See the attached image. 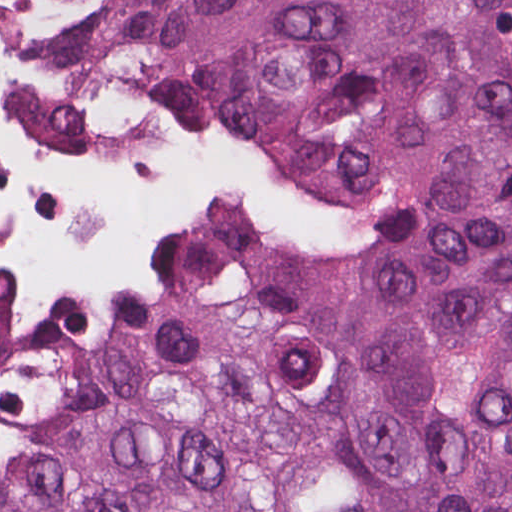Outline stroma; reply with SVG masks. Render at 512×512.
Segmentation results:
<instances>
[{"instance_id":"obj_1","label":"stroma","mask_w":512,"mask_h":512,"mask_svg":"<svg viewBox=\"0 0 512 512\" xmlns=\"http://www.w3.org/2000/svg\"><path fill=\"white\" fill-rule=\"evenodd\" d=\"M19 0H0V5ZM80 11L115 67L132 89L130 74L143 40L179 0H59ZM133 90V89H132ZM181 118V117H180ZM210 132L244 156L258 171L305 195L322 208L316 229L261 232L254 251L241 268H216L239 298L286 316L345 333L358 340L423 351H512V328L499 331H443L409 328L364 318L294 306L250 277V257L266 248L326 251L374 248L385 236L381 220L315 194L279 175L232 130L214 122L182 118ZM153 248H147L131 275L116 287L91 297L66 298L92 309L127 311L135 296V276ZM23 309L0 328V373L12 368L19 353Z\"/></svg>"}]
</instances>
